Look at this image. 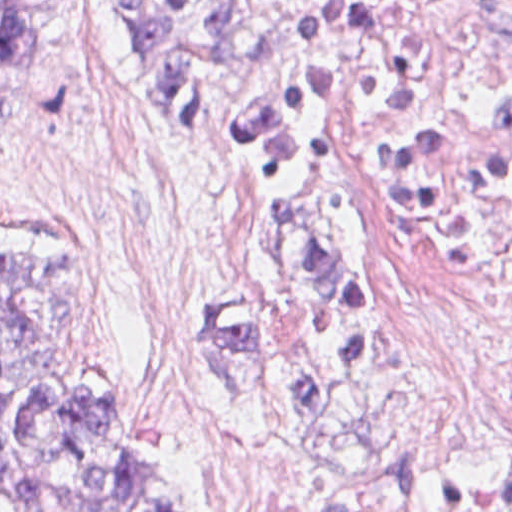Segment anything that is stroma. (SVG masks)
<instances>
[{"instance_id": "obj_1", "label": "stroma", "mask_w": 512, "mask_h": 512, "mask_svg": "<svg viewBox=\"0 0 512 512\" xmlns=\"http://www.w3.org/2000/svg\"><path fill=\"white\" fill-rule=\"evenodd\" d=\"M460 1L401 0L347 76L391 71ZM309 2L260 0L249 55L221 78L215 111L192 118L145 86L119 0H60L42 58L0 116V241L28 230L75 234L95 294L80 363L113 381L144 440L189 476L196 512H219L223 461L247 441L450 512H501L479 490L484 475L512 469V444L439 461L406 438L387 361L361 418L312 417L268 379L254 388L217 322L227 306L258 297L261 214L237 155L241 119ZM346 77L344 201L370 281L360 118ZM379 344L372 291L362 395Z\"/></svg>"}]
</instances>
